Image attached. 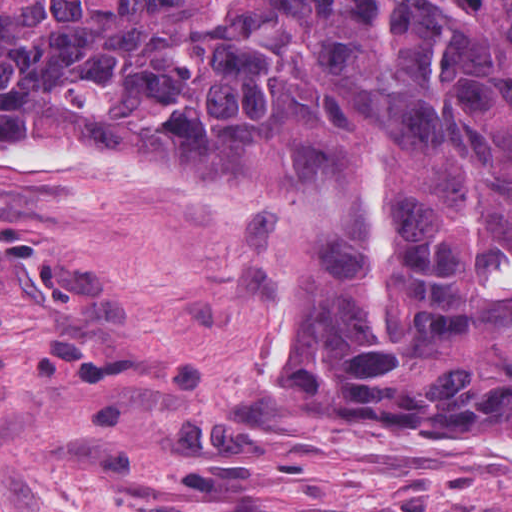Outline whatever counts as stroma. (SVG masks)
<instances>
[{
  "mask_svg": "<svg viewBox=\"0 0 512 512\" xmlns=\"http://www.w3.org/2000/svg\"><path fill=\"white\" fill-rule=\"evenodd\" d=\"M265 195L0 172V512H512L511 467L434 463L512 431L371 424L254 329Z\"/></svg>",
  "mask_w": 512,
  "mask_h": 512,
  "instance_id": "stroma-1",
  "label": "stroma"
}]
</instances>
